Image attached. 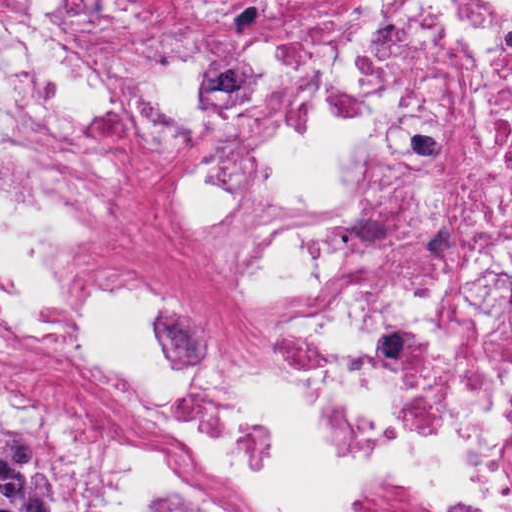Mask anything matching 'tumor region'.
Wrapping results in <instances>:
<instances>
[{
    "label": "tumor region",
    "instance_id": "e687c5a6",
    "mask_svg": "<svg viewBox=\"0 0 512 512\" xmlns=\"http://www.w3.org/2000/svg\"><path fill=\"white\" fill-rule=\"evenodd\" d=\"M0 512H69L40 469V455L25 437L0 429Z\"/></svg>",
    "mask_w": 512,
    "mask_h": 512
}]
</instances>
